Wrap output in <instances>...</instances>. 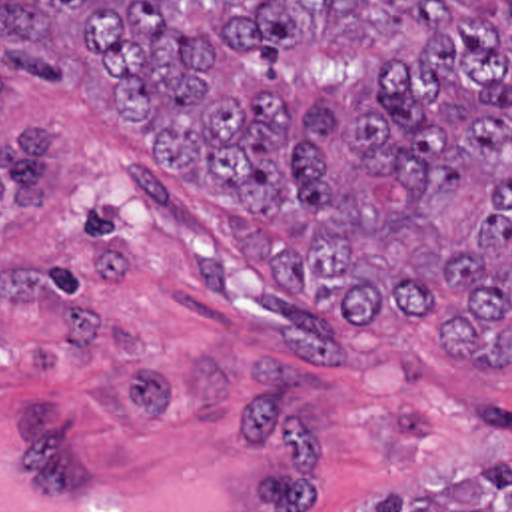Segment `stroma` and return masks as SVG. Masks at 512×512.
Instances as JSON below:
<instances>
[{"instance_id":"obj_1","label":"stroma","mask_w":512,"mask_h":512,"mask_svg":"<svg viewBox=\"0 0 512 512\" xmlns=\"http://www.w3.org/2000/svg\"><path fill=\"white\" fill-rule=\"evenodd\" d=\"M55 123L45 207L0 205V418L17 480L121 488L175 454L231 462L235 512H370L512 462V370L408 313H325L267 273L65 59L0 99Z\"/></svg>"}]
</instances>
